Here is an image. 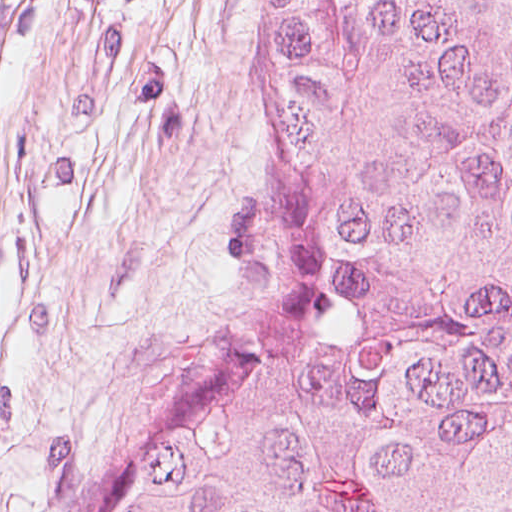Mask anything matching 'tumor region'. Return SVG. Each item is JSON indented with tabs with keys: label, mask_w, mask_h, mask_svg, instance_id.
Wrapping results in <instances>:
<instances>
[{
	"label": "tumor region",
	"mask_w": 512,
	"mask_h": 512,
	"mask_svg": "<svg viewBox=\"0 0 512 512\" xmlns=\"http://www.w3.org/2000/svg\"><path fill=\"white\" fill-rule=\"evenodd\" d=\"M256 335L68 512H512V0H271Z\"/></svg>",
	"instance_id": "tumor-region-1"
}]
</instances>
